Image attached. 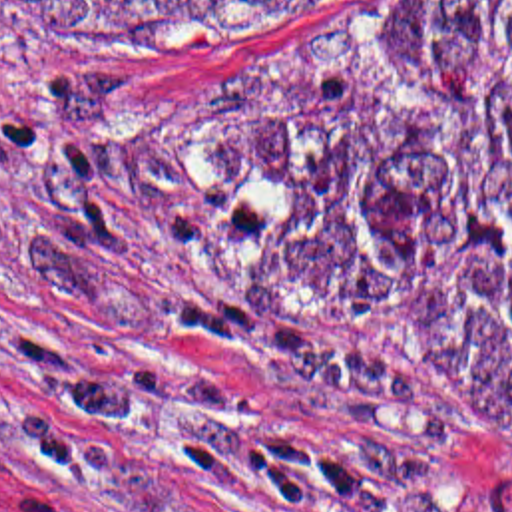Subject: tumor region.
Wrapping results in <instances>:
<instances>
[{
  "label": "tumor region",
  "mask_w": 512,
  "mask_h": 512,
  "mask_svg": "<svg viewBox=\"0 0 512 512\" xmlns=\"http://www.w3.org/2000/svg\"><path fill=\"white\" fill-rule=\"evenodd\" d=\"M303 31L359 0H10ZM263 306L512 439V0H432L385 55Z\"/></svg>",
  "instance_id": "1"
}]
</instances>
